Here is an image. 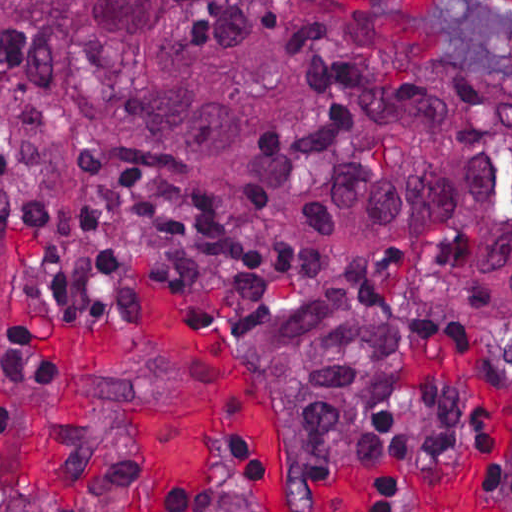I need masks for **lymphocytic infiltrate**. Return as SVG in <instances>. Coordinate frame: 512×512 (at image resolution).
I'll return each mask as SVG.
<instances>
[{"label":"lymphocytic infiltrate","mask_w":512,"mask_h":512,"mask_svg":"<svg viewBox=\"0 0 512 512\" xmlns=\"http://www.w3.org/2000/svg\"><path fill=\"white\" fill-rule=\"evenodd\" d=\"M0 218L13 234L19 283L28 301L75 312H108L130 256L174 264L194 300L241 325L265 287V255L247 235L179 207L100 191L0 185ZM32 331L31 326L18 324ZM486 485L512 486V403L477 434ZM155 512H187V493L169 492Z\"/></svg>","instance_id":"lymphocytic-infiltrate-1"}]
</instances>
